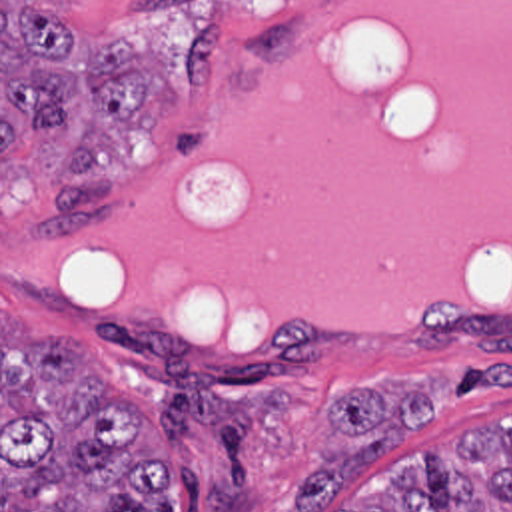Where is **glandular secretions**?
Segmentation results:
<instances>
[{
  "label": "glandular secretions",
  "instance_id": "glandular-secretions-1",
  "mask_svg": "<svg viewBox=\"0 0 512 512\" xmlns=\"http://www.w3.org/2000/svg\"><path fill=\"white\" fill-rule=\"evenodd\" d=\"M2 282L234 348L512 314V0H317L230 62L212 130L140 182L124 232L60 244L4 208Z\"/></svg>",
  "mask_w": 512,
  "mask_h": 512
}]
</instances>
